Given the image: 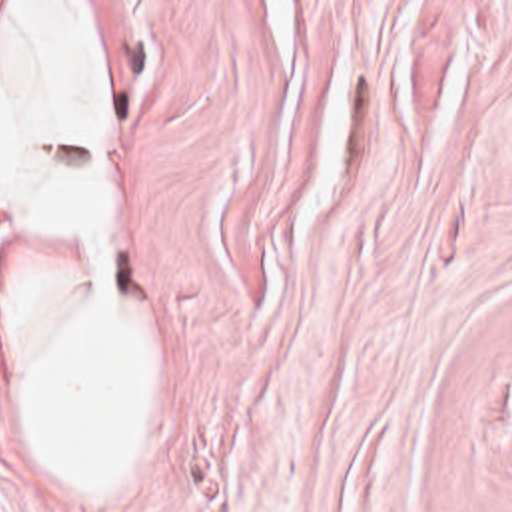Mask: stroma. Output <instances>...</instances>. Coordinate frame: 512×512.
Wrapping results in <instances>:
<instances>
[{
  "label": "stroma",
  "instance_id": "stroma-1",
  "mask_svg": "<svg viewBox=\"0 0 512 512\" xmlns=\"http://www.w3.org/2000/svg\"><path fill=\"white\" fill-rule=\"evenodd\" d=\"M71 3L155 395L49 476L15 323L87 259L0 209V512H512V0Z\"/></svg>",
  "mask_w": 512,
  "mask_h": 512
}]
</instances>
